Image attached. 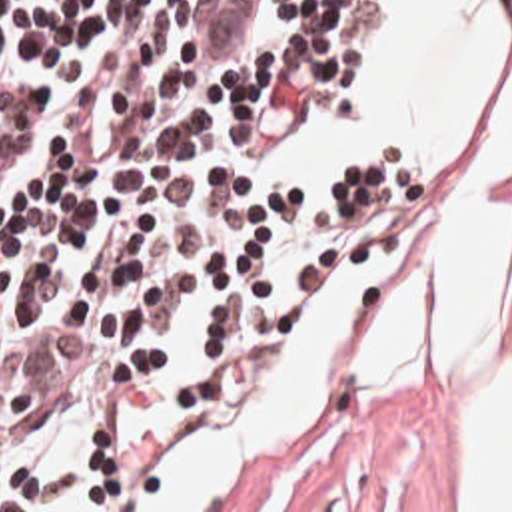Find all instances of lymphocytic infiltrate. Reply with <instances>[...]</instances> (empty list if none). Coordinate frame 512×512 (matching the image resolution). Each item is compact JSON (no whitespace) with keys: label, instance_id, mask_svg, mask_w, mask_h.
<instances>
[{"label":"lymphocytic infiltrate","instance_id":"lymphocytic-infiltrate-1","mask_svg":"<svg viewBox=\"0 0 512 512\" xmlns=\"http://www.w3.org/2000/svg\"><path fill=\"white\" fill-rule=\"evenodd\" d=\"M380 0H0V512L41 475L13 441L101 383L99 512H147L279 385L296 317L336 271L396 245V155L340 165L294 287L298 185L245 157L292 115L362 107Z\"/></svg>","mask_w":512,"mask_h":512}]
</instances>
